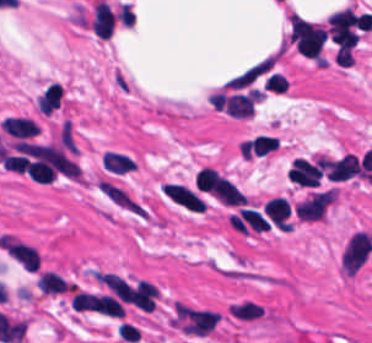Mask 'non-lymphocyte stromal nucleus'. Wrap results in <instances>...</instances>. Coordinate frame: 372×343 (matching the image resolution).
<instances>
[{
  "label": "non-lymphocyte stromal nucleus",
  "mask_w": 372,
  "mask_h": 343,
  "mask_svg": "<svg viewBox=\"0 0 372 343\" xmlns=\"http://www.w3.org/2000/svg\"><path fill=\"white\" fill-rule=\"evenodd\" d=\"M99 187L103 198L117 209L135 217L149 218L150 209L120 183L101 177Z\"/></svg>",
  "instance_id": "non-lymphocyte-stromal-nucleus-1"
},
{
  "label": "non-lymphocyte stromal nucleus",
  "mask_w": 372,
  "mask_h": 343,
  "mask_svg": "<svg viewBox=\"0 0 372 343\" xmlns=\"http://www.w3.org/2000/svg\"><path fill=\"white\" fill-rule=\"evenodd\" d=\"M265 313L266 305L247 297H240L227 306V315L240 323H256Z\"/></svg>",
  "instance_id": "non-lymphocyte-stromal-nucleus-2"
},
{
  "label": "non-lymphocyte stromal nucleus",
  "mask_w": 372,
  "mask_h": 343,
  "mask_svg": "<svg viewBox=\"0 0 372 343\" xmlns=\"http://www.w3.org/2000/svg\"><path fill=\"white\" fill-rule=\"evenodd\" d=\"M110 80L113 86L122 93L129 94L133 91L132 81L121 68H114Z\"/></svg>",
  "instance_id": "non-lymphocyte-stromal-nucleus-3"
}]
</instances>
